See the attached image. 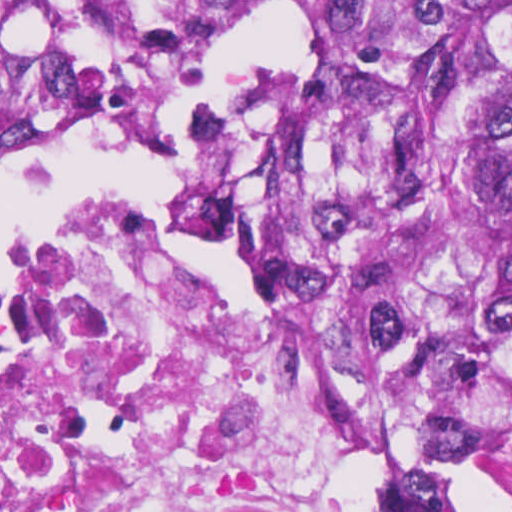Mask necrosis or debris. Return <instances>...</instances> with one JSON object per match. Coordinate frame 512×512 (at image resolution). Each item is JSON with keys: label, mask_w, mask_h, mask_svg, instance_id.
I'll list each match as a JSON object with an SVG mask.
<instances>
[{"label": "necrosis or debris", "mask_w": 512, "mask_h": 512, "mask_svg": "<svg viewBox=\"0 0 512 512\" xmlns=\"http://www.w3.org/2000/svg\"><path fill=\"white\" fill-rule=\"evenodd\" d=\"M223 122L204 193L221 275L160 201L0 280V512H338L228 263L237 111Z\"/></svg>", "instance_id": "4bbe7bcc"}]
</instances>
